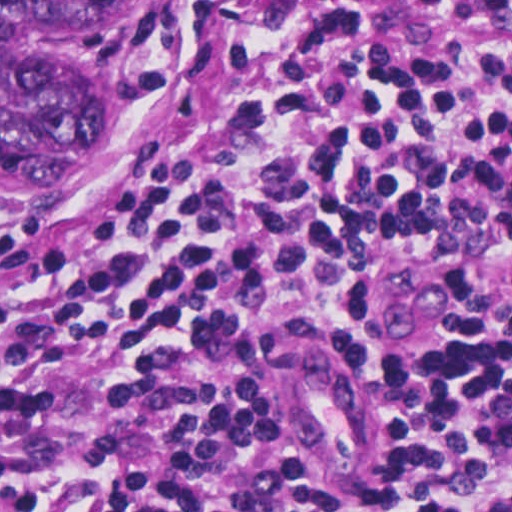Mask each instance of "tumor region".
Wrapping results in <instances>:
<instances>
[{"instance_id":"1","label":"tumor region","mask_w":512,"mask_h":512,"mask_svg":"<svg viewBox=\"0 0 512 512\" xmlns=\"http://www.w3.org/2000/svg\"><path fill=\"white\" fill-rule=\"evenodd\" d=\"M113 2L0 0V196L48 189L114 124L120 68L106 25ZM361 274L351 281L357 296Z\"/></svg>"}]
</instances>
